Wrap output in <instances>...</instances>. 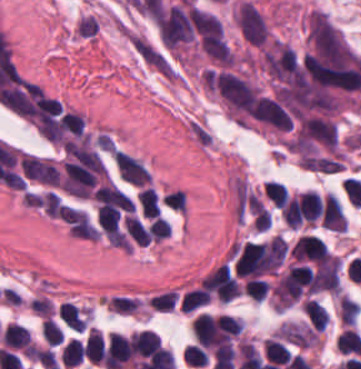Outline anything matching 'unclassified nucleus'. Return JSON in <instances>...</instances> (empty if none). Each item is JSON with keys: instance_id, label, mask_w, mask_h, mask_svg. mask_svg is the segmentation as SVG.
I'll use <instances>...</instances> for the list:
<instances>
[{"instance_id": "unclassified-nucleus-3", "label": "unclassified nucleus", "mask_w": 361, "mask_h": 369, "mask_svg": "<svg viewBox=\"0 0 361 369\" xmlns=\"http://www.w3.org/2000/svg\"><path fill=\"white\" fill-rule=\"evenodd\" d=\"M142 217H155L160 209L158 196L154 188L142 187L137 194Z\"/></svg>"}, {"instance_id": "unclassified-nucleus-4", "label": "unclassified nucleus", "mask_w": 361, "mask_h": 369, "mask_svg": "<svg viewBox=\"0 0 361 369\" xmlns=\"http://www.w3.org/2000/svg\"><path fill=\"white\" fill-rule=\"evenodd\" d=\"M127 231L133 242L148 245V230L142 221L135 215H128L124 217Z\"/></svg>"}, {"instance_id": "unclassified-nucleus-2", "label": "unclassified nucleus", "mask_w": 361, "mask_h": 369, "mask_svg": "<svg viewBox=\"0 0 361 369\" xmlns=\"http://www.w3.org/2000/svg\"><path fill=\"white\" fill-rule=\"evenodd\" d=\"M113 154L122 180L137 187H144L148 183L149 173L138 158L122 149H114Z\"/></svg>"}, {"instance_id": "unclassified-nucleus-6", "label": "unclassified nucleus", "mask_w": 361, "mask_h": 369, "mask_svg": "<svg viewBox=\"0 0 361 369\" xmlns=\"http://www.w3.org/2000/svg\"><path fill=\"white\" fill-rule=\"evenodd\" d=\"M162 203L178 212L187 210V194L182 189H175L162 197Z\"/></svg>"}, {"instance_id": "unclassified-nucleus-5", "label": "unclassified nucleus", "mask_w": 361, "mask_h": 369, "mask_svg": "<svg viewBox=\"0 0 361 369\" xmlns=\"http://www.w3.org/2000/svg\"><path fill=\"white\" fill-rule=\"evenodd\" d=\"M172 229L168 221L162 217H154L149 222L148 238L154 241H162L169 237Z\"/></svg>"}, {"instance_id": "unclassified-nucleus-1", "label": "unclassified nucleus", "mask_w": 361, "mask_h": 369, "mask_svg": "<svg viewBox=\"0 0 361 369\" xmlns=\"http://www.w3.org/2000/svg\"><path fill=\"white\" fill-rule=\"evenodd\" d=\"M23 174L42 184L56 186L59 180V167L48 157L23 153L20 158Z\"/></svg>"}]
</instances>
